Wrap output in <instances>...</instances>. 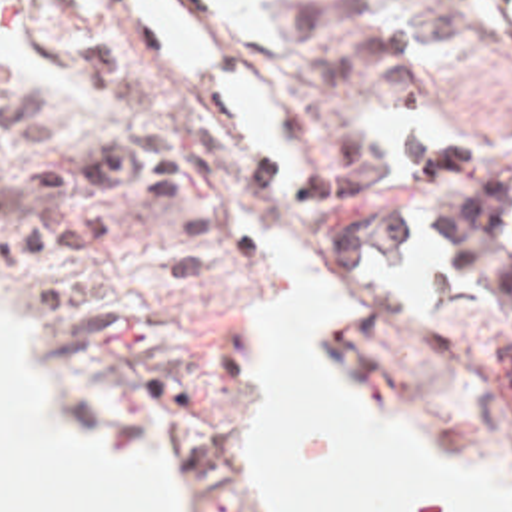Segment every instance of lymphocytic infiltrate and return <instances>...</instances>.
I'll use <instances>...</instances> for the list:
<instances>
[{
    "label": "lymphocytic infiltrate",
    "instance_id": "f902f5d3",
    "mask_svg": "<svg viewBox=\"0 0 512 512\" xmlns=\"http://www.w3.org/2000/svg\"><path fill=\"white\" fill-rule=\"evenodd\" d=\"M82 84L115 110L111 134L98 146L32 168L0 156V228L8 246L38 254L94 244L113 220L92 206L52 204L80 186H107L151 222L157 273L171 285L209 279V210L195 204L175 136L147 110L137 78L100 42L76 48ZM0 62V148L36 152L58 134L52 94Z\"/></svg>",
    "mask_w": 512,
    "mask_h": 512
}]
</instances>
